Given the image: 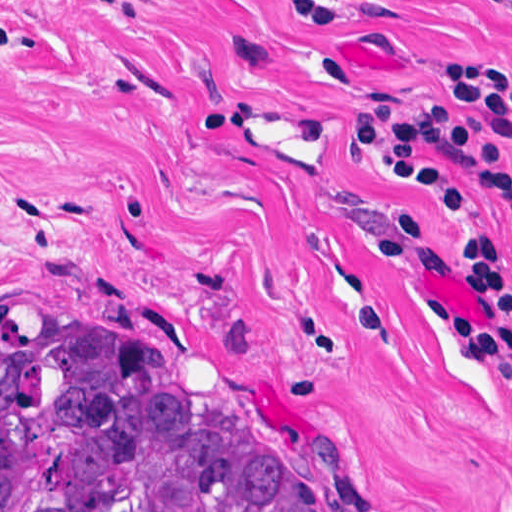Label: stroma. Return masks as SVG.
<instances>
[{
  "instance_id": "stroma-1",
  "label": "stroma",
  "mask_w": 512,
  "mask_h": 512,
  "mask_svg": "<svg viewBox=\"0 0 512 512\" xmlns=\"http://www.w3.org/2000/svg\"><path fill=\"white\" fill-rule=\"evenodd\" d=\"M346 1L0 0V340L229 402L333 512H512V401L376 252L403 208L417 286L465 309L448 225L345 127L446 55L512 67V10Z\"/></svg>"
}]
</instances>
